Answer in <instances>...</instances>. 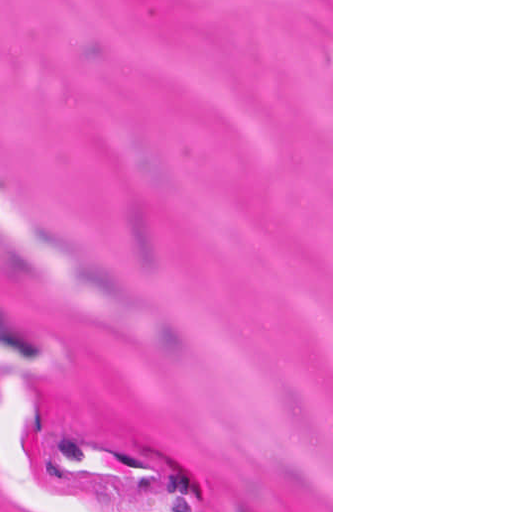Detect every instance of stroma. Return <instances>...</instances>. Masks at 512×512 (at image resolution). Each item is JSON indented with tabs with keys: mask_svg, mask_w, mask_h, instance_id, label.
<instances>
[{
	"mask_svg": "<svg viewBox=\"0 0 512 512\" xmlns=\"http://www.w3.org/2000/svg\"><path fill=\"white\" fill-rule=\"evenodd\" d=\"M0 512H333V0H0Z\"/></svg>",
	"mask_w": 512,
	"mask_h": 512,
	"instance_id": "35a3bbf8",
	"label": "stroma"
}]
</instances>
